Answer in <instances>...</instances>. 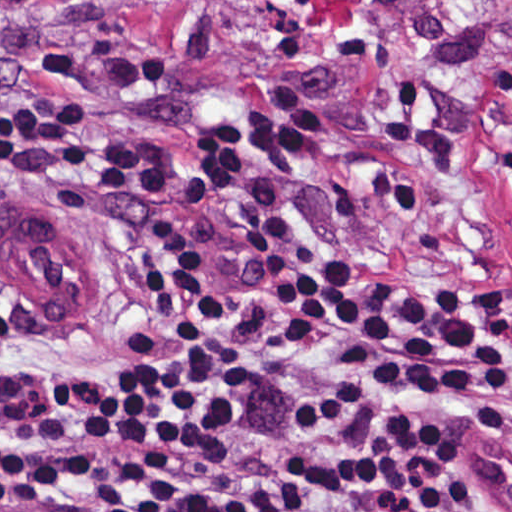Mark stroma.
I'll list each match as a JSON object with an SVG mask.
<instances>
[{"label":"stroma","instance_id":"1","mask_svg":"<svg viewBox=\"0 0 512 512\" xmlns=\"http://www.w3.org/2000/svg\"><path fill=\"white\" fill-rule=\"evenodd\" d=\"M0 85L111 102L182 177L154 193L0 191L49 210L90 257L60 321L0 279V357L36 373L94 363L126 249L164 237L221 257L249 388V440L211 478L270 462L289 512H323L293 467V391L312 347L224 215L219 176L284 194L351 269L459 292L512 326V0H71L0 39ZM512 484V379L450 455L442 504ZM0 512H28L0 482Z\"/></svg>","mask_w":512,"mask_h":512}]
</instances>
